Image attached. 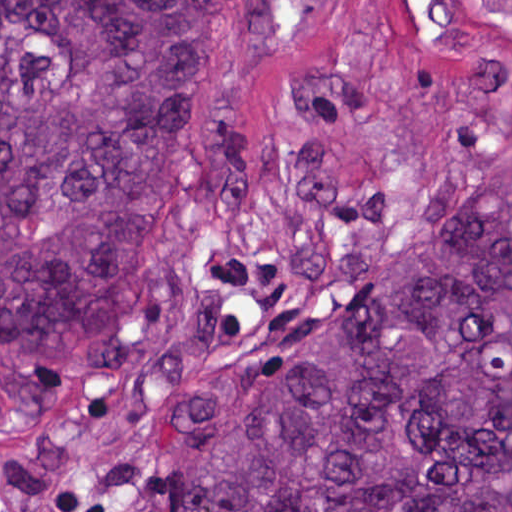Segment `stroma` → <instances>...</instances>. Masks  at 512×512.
<instances>
[{
	"label": "stroma",
	"instance_id": "obj_1",
	"mask_svg": "<svg viewBox=\"0 0 512 512\" xmlns=\"http://www.w3.org/2000/svg\"><path fill=\"white\" fill-rule=\"evenodd\" d=\"M512 171V14L269 0L245 131L134 263L121 334L0 351V512H160L221 386L453 225Z\"/></svg>",
	"mask_w": 512,
	"mask_h": 512
}]
</instances>
